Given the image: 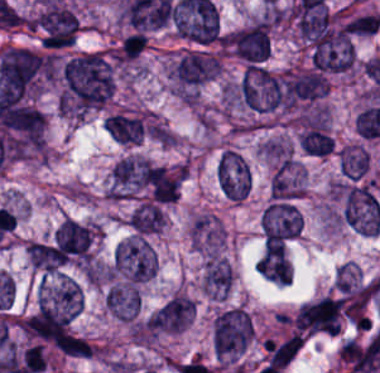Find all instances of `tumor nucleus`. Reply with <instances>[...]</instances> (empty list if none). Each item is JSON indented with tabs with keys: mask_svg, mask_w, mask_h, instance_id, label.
<instances>
[{
	"mask_svg": "<svg viewBox=\"0 0 380 373\" xmlns=\"http://www.w3.org/2000/svg\"><path fill=\"white\" fill-rule=\"evenodd\" d=\"M304 193L303 164L285 158L272 175L270 197H298Z\"/></svg>",
	"mask_w": 380,
	"mask_h": 373,
	"instance_id": "tumor-nucleus-7",
	"label": "tumor nucleus"
},
{
	"mask_svg": "<svg viewBox=\"0 0 380 373\" xmlns=\"http://www.w3.org/2000/svg\"><path fill=\"white\" fill-rule=\"evenodd\" d=\"M99 229L66 219L55 232V242L63 255L80 263H88L93 254Z\"/></svg>",
	"mask_w": 380,
	"mask_h": 373,
	"instance_id": "tumor-nucleus-5",
	"label": "tumor nucleus"
},
{
	"mask_svg": "<svg viewBox=\"0 0 380 373\" xmlns=\"http://www.w3.org/2000/svg\"><path fill=\"white\" fill-rule=\"evenodd\" d=\"M102 126L118 143H137L143 134L141 116L110 113Z\"/></svg>",
	"mask_w": 380,
	"mask_h": 373,
	"instance_id": "tumor-nucleus-10",
	"label": "tumor nucleus"
},
{
	"mask_svg": "<svg viewBox=\"0 0 380 373\" xmlns=\"http://www.w3.org/2000/svg\"><path fill=\"white\" fill-rule=\"evenodd\" d=\"M301 215L291 201L270 198L259 214L264 249L294 239L299 232Z\"/></svg>",
	"mask_w": 380,
	"mask_h": 373,
	"instance_id": "tumor-nucleus-3",
	"label": "tumor nucleus"
},
{
	"mask_svg": "<svg viewBox=\"0 0 380 373\" xmlns=\"http://www.w3.org/2000/svg\"><path fill=\"white\" fill-rule=\"evenodd\" d=\"M153 270V253L141 235H130L120 241L108 267L109 280L142 284Z\"/></svg>",
	"mask_w": 380,
	"mask_h": 373,
	"instance_id": "tumor-nucleus-1",
	"label": "tumor nucleus"
},
{
	"mask_svg": "<svg viewBox=\"0 0 380 373\" xmlns=\"http://www.w3.org/2000/svg\"><path fill=\"white\" fill-rule=\"evenodd\" d=\"M255 269L269 282L288 285L290 267L282 241L263 250Z\"/></svg>",
	"mask_w": 380,
	"mask_h": 373,
	"instance_id": "tumor-nucleus-9",
	"label": "tumor nucleus"
},
{
	"mask_svg": "<svg viewBox=\"0 0 380 373\" xmlns=\"http://www.w3.org/2000/svg\"><path fill=\"white\" fill-rule=\"evenodd\" d=\"M232 281L230 265L220 258L210 256L204 262L200 287L206 297H226Z\"/></svg>",
	"mask_w": 380,
	"mask_h": 373,
	"instance_id": "tumor-nucleus-8",
	"label": "tumor nucleus"
},
{
	"mask_svg": "<svg viewBox=\"0 0 380 373\" xmlns=\"http://www.w3.org/2000/svg\"><path fill=\"white\" fill-rule=\"evenodd\" d=\"M342 220L353 230L378 232L380 207L366 184L334 188Z\"/></svg>",
	"mask_w": 380,
	"mask_h": 373,
	"instance_id": "tumor-nucleus-2",
	"label": "tumor nucleus"
},
{
	"mask_svg": "<svg viewBox=\"0 0 380 373\" xmlns=\"http://www.w3.org/2000/svg\"><path fill=\"white\" fill-rule=\"evenodd\" d=\"M298 141L305 153L325 157L331 153L333 139L318 125H311L302 130Z\"/></svg>",
	"mask_w": 380,
	"mask_h": 373,
	"instance_id": "tumor-nucleus-13",
	"label": "tumor nucleus"
},
{
	"mask_svg": "<svg viewBox=\"0 0 380 373\" xmlns=\"http://www.w3.org/2000/svg\"><path fill=\"white\" fill-rule=\"evenodd\" d=\"M104 305L120 321L135 322L140 309V292L136 284L116 282L105 291Z\"/></svg>",
	"mask_w": 380,
	"mask_h": 373,
	"instance_id": "tumor-nucleus-6",
	"label": "tumor nucleus"
},
{
	"mask_svg": "<svg viewBox=\"0 0 380 373\" xmlns=\"http://www.w3.org/2000/svg\"><path fill=\"white\" fill-rule=\"evenodd\" d=\"M30 266L48 274H58L64 257L56 246L30 242L26 248Z\"/></svg>",
	"mask_w": 380,
	"mask_h": 373,
	"instance_id": "tumor-nucleus-12",
	"label": "tumor nucleus"
},
{
	"mask_svg": "<svg viewBox=\"0 0 380 373\" xmlns=\"http://www.w3.org/2000/svg\"><path fill=\"white\" fill-rule=\"evenodd\" d=\"M216 181L230 201H244L251 188V172L245 158L231 149H224L218 159Z\"/></svg>",
	"mask_w": 380,
	"mask_h": 373,
	"instance_id": "tumor-nucleus-4",
	"label": "tumor nucleus"
},
{
	"mask_svg": "<svg viewBox=\"0 0 380 373\" xmlns=\"http://www.w3.org/2000/svg\"><path fill=\"white\" fill-rule=\"evenodd\" d=\"M369 166L366 145L344 144L339 149V169L345 177H366Z\"/></svg>",
	"mask_w": 380,
	"mask_h": 373,
	"instance_id": "tumor-nucleus-11",
	"label": "tumor nucleus"
}]
</instances>
